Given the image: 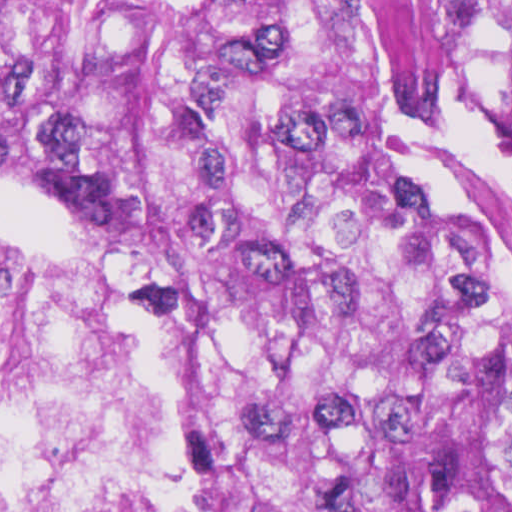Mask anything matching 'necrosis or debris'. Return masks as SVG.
I'll use <instances>...</instances> for the list:
<instances>
[{
    "label": "necrosis or debris",
    "mask_w": 512,
    "mask_h": 512,
    "mask_svg": "<svg viewBox=\"0 0 512 512\" xmlns=\"http://www.w3.org/2000/svg\"><path fill=\"white\" fill-rule=\"evenodd\" d=\"M0 512H214L176 397L147 392L66 262L8 238Z\"/></svg>",
    "instance_id": "1"
}]
</instances>
